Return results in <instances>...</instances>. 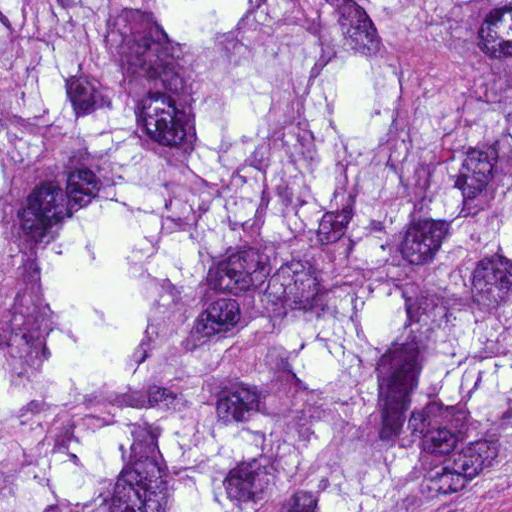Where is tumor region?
<instances>
[{
	"instance_id": "tumor-region-1",
	"label": "tumor region",
	"mask_w": 512,
	"mask_h": 512,
	"mask_svg": "<svg viewBox=\"0 0 512 512\" xmlns=\"http://www.w3.org/2000/svg\"><path fill=\"white\" fill-rule=\"evenodd\" d=\"M0 512H512V0H0Z\"/></svg>"
}]
</instances>
